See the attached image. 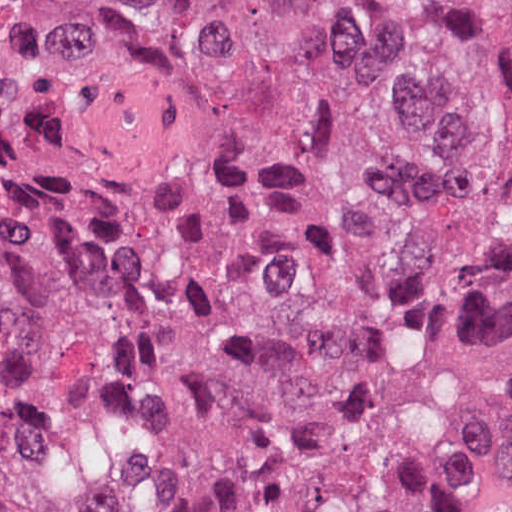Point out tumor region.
I'll list each match as a JSON object with an SVG mask.
<instances>
[{
    "mask_svg": "<svg viewBox=\"0 0 512 512\" xmlns=\"http://www.w3.org/2000/svg\"><path fill=\"white\" fill-rule=\"evenodd\" d=\"M511 484L512 0H0V512Z\"/></svg>",
    "mask_w": 512,
    "mask_h": 512,
    "instance_id": "e687c5a6",
    "label": "tumor region"
}]
</instances>
